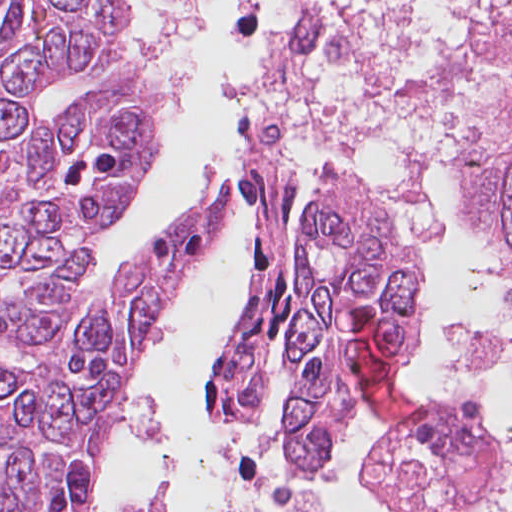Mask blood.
Segmentation results:
<instances>
[{
	"instance_id": "blood-1",
	"label": "blood",
	"mask_w": 512,
	"mask_h": 512,
	"mask_svg": "<svg viewBox=\"0 0 512 512\" xmlns=\"http://www.w3.org/2000/svg\"><path fill=\"white\" fill-rule=\"evenodd\" d=\"M352 337L372 398L392 420L411 423L420 404L400 373V347L388 325L369 306L361 307Z\"/></svg>"
}]
</instances>
